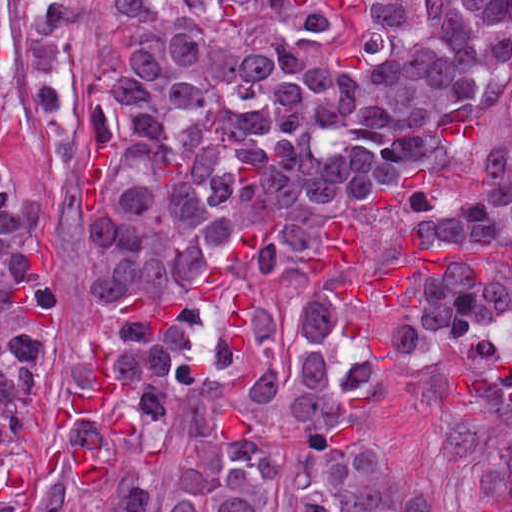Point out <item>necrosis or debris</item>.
<instances>
[{
    "label": "necrosis or debris",
    "mask_w": 512,
    "mask_h": 512,
    "mask_svg": "<svg viewBox=\"0 0 512 512\" xmlns=\"http://www.w3.org/2000/svg\"><path fill=\"white\" fill-rule=\"evenodd\" d=\"M464 357L484 365L512 367V312H495L479 321Z\"/></svg>",
    "instance_id": "necrosis-or-debris-1"
}]
</instances>
